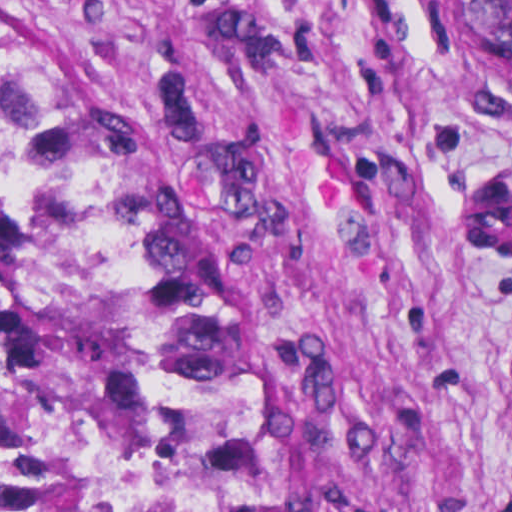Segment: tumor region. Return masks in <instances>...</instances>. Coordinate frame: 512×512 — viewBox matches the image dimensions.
I'll return each instance as SVG.
<instances>
[{"label": "tumor region", "mask_w": 512, "mask_h": 512, "mask_svg": "<svg viewBox=\"0 0 512 512\" xmlns=\"http://www.w3.org/2000/svg\"><path fill=\"white\" fill-rule=\"evenodd\" d=\"M479 4L486 66L512 100V0ZM29 252L72 280L145 512H300L232 324L95 185L0 47V290Z\"/></svg>", "instance_id": "e687c5a6"}]
</instances>
